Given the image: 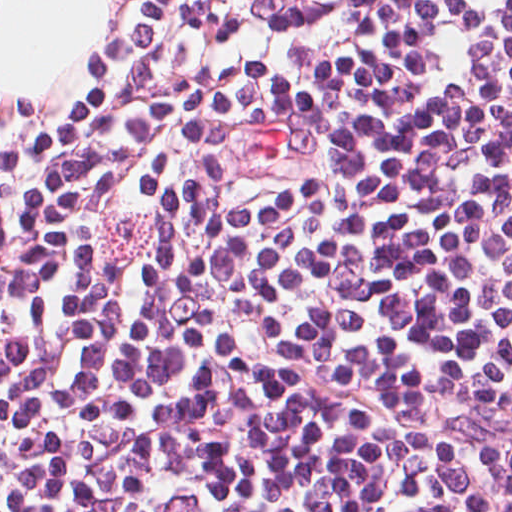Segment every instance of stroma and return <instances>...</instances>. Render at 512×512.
Listing matches in <instances>:
<instances>
[{
  "instance_id": "35a3bbf8",
  "label": "stroma",
  "mask_w": 512,
  "mask_h": 512,
  "mask_svg": "<svg viewBox=\"0 0 512 512\" xmlns=\"http://www.w3.org/2000/svg\"><path fill=\"white\" fill-rule=\"evenodd\" d=\"M131 0H108L102 28L72 72L56 81L39 108L0 97V135L10 134L75 96L114 67Z\"/></svg>"
}]
</instances>
